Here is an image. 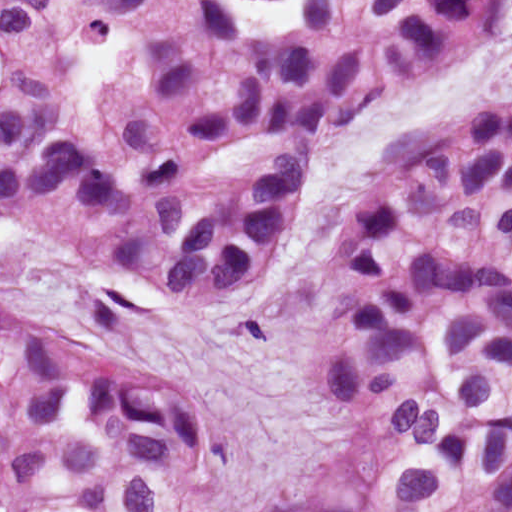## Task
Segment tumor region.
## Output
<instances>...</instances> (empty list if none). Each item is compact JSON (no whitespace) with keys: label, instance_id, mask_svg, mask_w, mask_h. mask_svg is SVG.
Returning <instances> with one entry per match:
<instances>
[{"label":"tumor region","instance_id":"tumor-region-1","mask_svg":"<svg viewBox=\"0 0 512 512\" xmlns=\"http://www.w3.org/2000/svg\"><path fill=\"white\" fill-rule=\"evenodd\" d=\"M512 33V0H0V210L204 320L264 283L316 164ZM314 395L351 463L259 512H512V92L407 123L324 236ZM219 427L0 332V512H228Z\"/></svg>","mask_w":512,"mask_h":512}]
</instances>
